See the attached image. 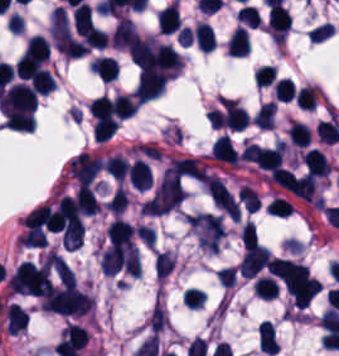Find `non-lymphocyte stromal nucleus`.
I'll return each instance as SVG.
<instances>
[{"mask_svg":"<svg viewBox=\"0 0 339 356\" xmlns=\"http://www.w3.org/2000/svg\"><path fill=\"white\" fill-rule=\"evenodd\" d=\"M206 190L215 204L232 220L238 221L239 205L222 181L211 175L206 180Z\"/></svg>","mask_w":339,"mask_h":356,"instance_id":"obj_5","label":"non-lymphocyte stromal nucleus"},{"mask_svg":"<svg viewBox=\"0 0 339 356\" xmlns=\"http://www.w3.org/2000/svg\"><path fill=\"white\" fill-rule=\"evenodd\" d=\"M185 189L180 178L160 177L147 198L142 210L146 215H161L176 207L184 198Z\"/></svg>","mask_w":339,"mask_h":356,"instance_id":"obj_1","label":"non-lymphocyte stromal nucleus"},{"mask_svg":"<svg viewBox=\"0 0 339 356\" xmlns=\"http://www.w3.org/2000/svg\"><path fill=\"white\" fill-rule=\"evenodd\" d=\"M269 263L270 252L261 244L256 243L244 250L237 268L240 275L252 278L265 269Z\"/></svg>","mask_w":339,"mask_h":356,"instance_id":"obj_4","label":"non-lymphocyte stromal nucleus"},{"mask_svg":"<svg viewBox=\"0 0 339 356\" xmlns=\"http://www.w3.org/2000/svg\"><path fill=\"white\" fill-rule=\"evenodd\" d=\"M44 262L63 283H73L74 272L56 250H49Z\"/></svg>","mask_w":339,"mask_h":356,"instance_id":"obj_7","label":"non-lymphocyte stromal nucleus"},{"mask_svg":"<svg viewBox=\"0 0 339 356\" xmlns=\"http://www.w3.org/2000/svg\"><path fill=\"white\" fill-rule=\"evenodd\" d=\"M48 33L60 54L64 57H74V42L64 8L55 5L50 17Z\"/></svg>","mask_w":339,"mask_h":356,"instance_id":"obj_3","label":"non-lymphocyte stromal nucleus"},{"mask_svg":"<svg viewBox=\"0 0 339 356\" xmlns=\"http://www.w3.org/2000/svg\"><path fill=\"white\" fill-rule=\"evenodd\" d=\"M205 167L197 157L184 156L172 159L161 177L202 179Z\"/></svg>","mask_w":339,"mask_h":356,"instance_id":"obj_6","label":"non-lymphocyte stromal nucleus"},{"mask_svg":"<svg viewBox=\"0 0 339 356\" xmlns=\"http://www.w3.org/2000/svg\"><path fill=\"white\" fill-rule=\"evenodd\" d=\"M187 218L199 245L211 253H218L226 232L222 218L207 211H199Z\"/></svg>","mask_w":339,"mask_h":356,"instance_id":"obj_2","label":"non-lymphocyte stromal nucleus"}]
</instances>
